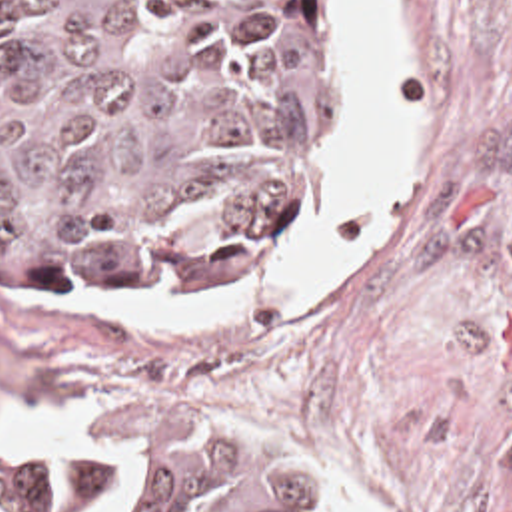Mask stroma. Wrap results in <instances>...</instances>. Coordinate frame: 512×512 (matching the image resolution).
I'll return each instance as SVG.
<instances>
[{"instance_id": "obj_1", "label": "stroma", "mask_w": 512, "mask_h": 512, "mask_svg": "<svg viewBox=\"0 0 512 512\" xmlns=\"http://www.w3.org/2000/svg\"><path fill=\"white\" fill-rule=\"evenodd\" d=\"M373 193L381 139L361 11ZM411 21V217L361 273L265 321L135 329L113 311L243 299L313 275L367 211L289 275L165 299H23L0 283V425L81 405L79 446L135 405L267 425L329 492L373 512H512V0H401ZM371 205V203H369ZM45 450H0V498L31 512Z\"/></svg>"}]
</instances>
